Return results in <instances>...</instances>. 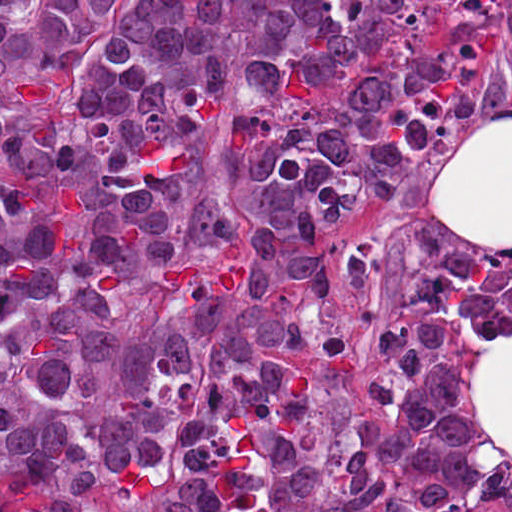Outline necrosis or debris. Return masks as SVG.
Here are the masks:
<instances>
[{"instance_id":"4bbe7bcc","label":"necrosis or debris","mask_w":512,"mask_h":512,"mask_svg":"<svg viewBox=\"0 0 512 512\" xmlns=\"http://www.w3.org/2000/svg\"><path fill=\"white\" fill-rule=\"evenodd\" d=\"M340 6L342 22L360 26L368 13V0H336Z\"/></svg>"}]
</instances>
